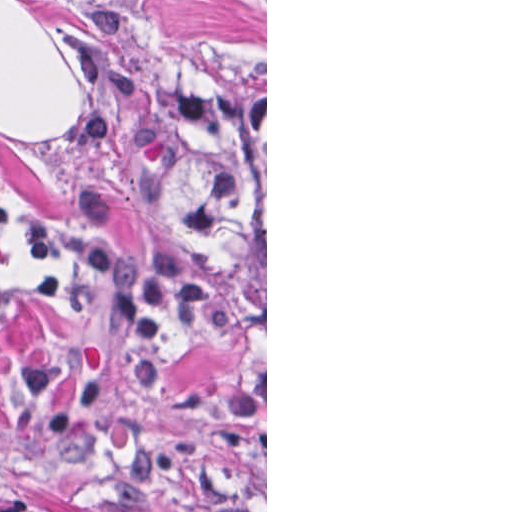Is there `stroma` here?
<instances>
[{
  "label": "stroma",
  "mask_w": 512,
  "mask_h": 512,
  "mask_svg": "<svg viewBox=\"0 0 512 512\" xmlns=\"http://www.w3.org/2000/svg\"><path fill=\"white\" fill-rule=\"evenodd\" d=\"M20 1L71 71L20 139ZM265 65V308L157 211L155 49ZM267 512V0H0V511Z\"/></svg>",
  "instance_id": "stroma-1"
}]
</instances>
